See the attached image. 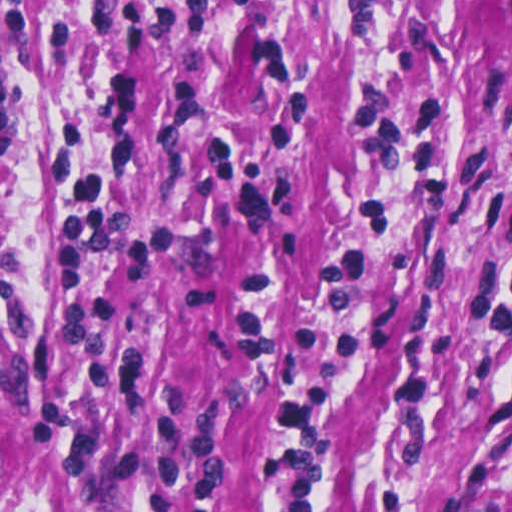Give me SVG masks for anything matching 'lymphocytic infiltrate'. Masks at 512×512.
<instances>
[{"instance_id": "lymphocytic-infiltrate-1", "label": "lymphocytic infiltrate", "mask_w": 512, "mask_h": 512, "mask_svg": "<svg viewBox=\"0 0 512 512\" xmlns=\"http://www.w3.org/2000/svg\"><path fill=\"white\" fill-rule=\"evenodd\" d=\"M357 123L375 163L359 189L346 241L320 260L324 313L314 331L295 334L276 319V276L260 264L248 277L236 318L242 353L264 360L279 391L261 460L258 512H327L332 499V414L357 364L353 332L373 273L404 239L406 218L390 197L414 185L432 201L453 182L458 105L441 93L404 98L392 85L354 86ZM483 223L512 240V191L478 206ZM462 323L494 334L512 353V257L482 258L461 299ZM487 411L512 424V363L496 377Z\"/></svg>"}]
</instances>
